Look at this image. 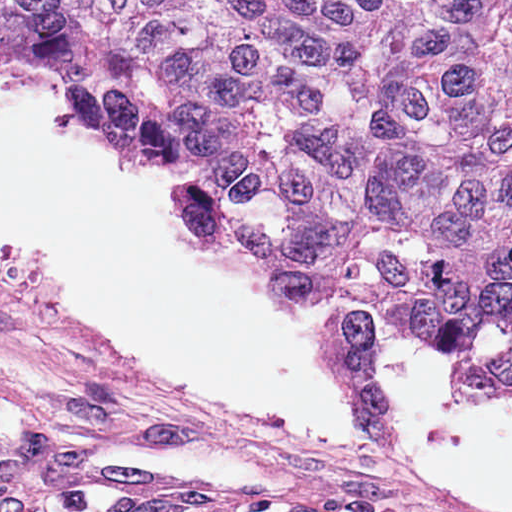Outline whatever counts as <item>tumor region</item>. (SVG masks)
Listing matches in <instances>:
<instances>
[{"label":"tumor region","instance_id":"tumor-region-1","mask_svg":"<svg viewBox=\"0 0 512 512\" xmlns=\"http://www.w3.org/2000/svg\"><path fill=\"white\" fill-rule=\"evenodd\" d=\"M106 137L319 305L512 390V0H26Z\"/></svg>","mask_w":512,"mask_h":512}]
</instances>
